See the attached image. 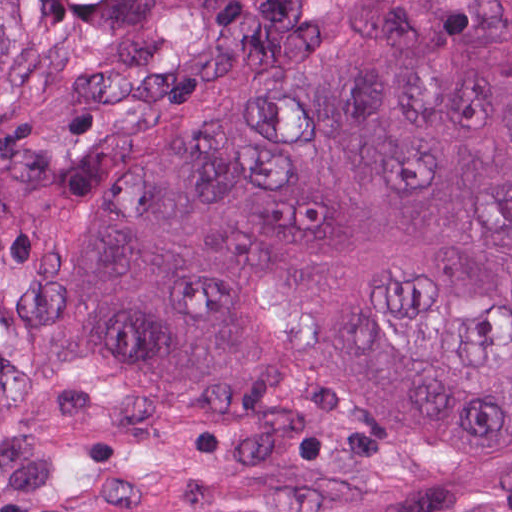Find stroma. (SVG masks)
Here are the masks:
<instances>
[{
  "instance_id": "1",
  "label": "stroma",
  "mask_w": 512,
  "mask_h": 512,
  "mask_svg": "<svg viewBox=\"0 0 512 512\" xmlns=\"http://www.w3.org/2000/svg\"><path fill=\"white\" fill-rule=\"evenodd\" d=\"M28 358L18 329L0 299V434L21 401Z\"/></svg>"
}]
</instances>
